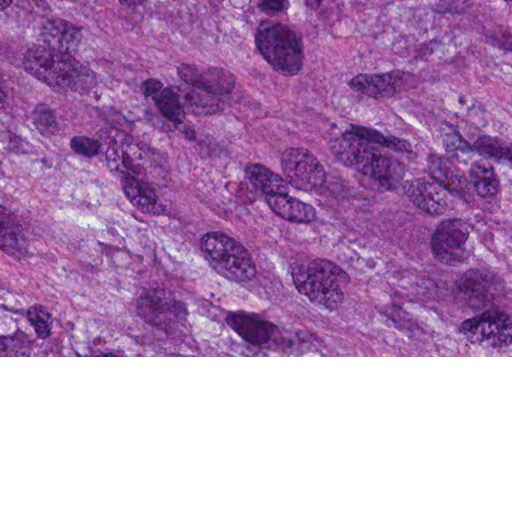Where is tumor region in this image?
I'll list each match as a JSON object with an SVG mask.
<instances>
[{
  "instance_id": "1",
  "label": "tumor region",
  "mask_w": 512,
  "mask_h": 512,
  "mask_svg": "<svg viewBox=\"0 0 512 512\" xmlns=\"http://www.w3.org/2000/svg\"><path fill=\"white\" fill-rule=\"evenodd\" d=\"M0 356H512V0H0Z\"/></svg>"
}]
</instances>
